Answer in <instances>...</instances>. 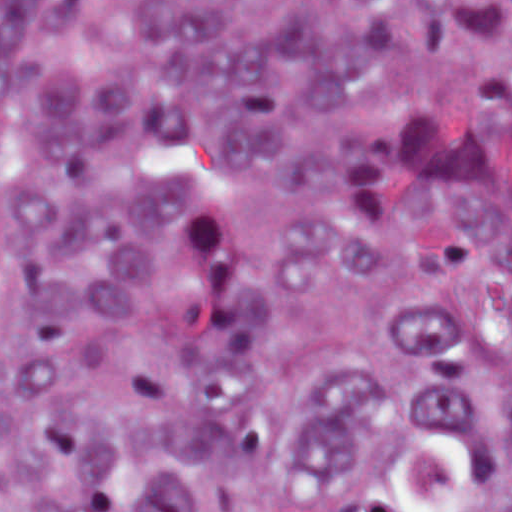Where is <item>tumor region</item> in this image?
<instances>
[{
    "instance_id": "e687c5a6",
    "label": "tumor region",
    "mask_w": 512,
    "mask_h": 512,
    "mask_svg": "<svg viewBox=\"0 0 512 512\" xmlns=\"http://www.w3.org/2000/svg\"><path fill=\"white\" fill-rule=\"evenodd\" d=\"M0 512H512V1H0Z\"/></svg>"
}]
</instances>
